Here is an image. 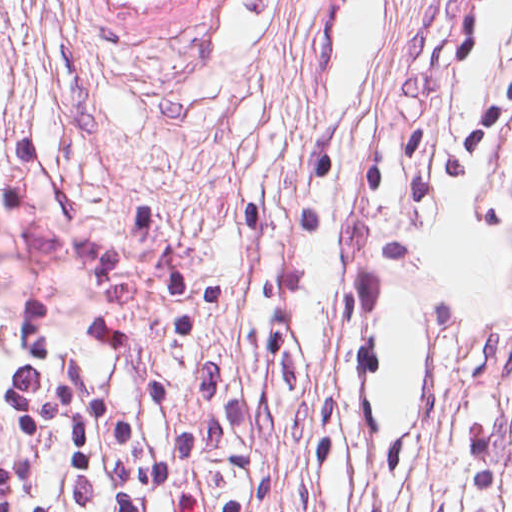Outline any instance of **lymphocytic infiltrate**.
Here are the masks:
<instances>
[{
	"mask_svg": "<svg viewBox=\"0 0 512 512\" xmlns=\"http://www.w3.org/2000/svg\"><path fill=\"white\" fill-rule=\"evenodd\" d=\"M506 1L446 0L445 24L426 25L421 59L455 71L476 66L496 41ZM511 144L512 59L446 122L307 156L288 225L313 238L354 222L432 214ZM510 226L488 240L497 253ZM511 408L512 308L493 341L471 512L503 505ZM211 474L199 416L148 343L0 303V512H212Z\"/></svg>",
	"mask_w": 512,
	"mask_h": 512,
	"instance_id": "1",
	"label": "lymphocytic infiltrate"
}]
</instances>
